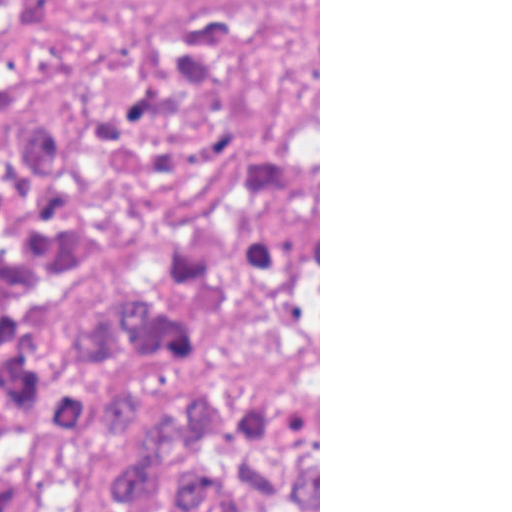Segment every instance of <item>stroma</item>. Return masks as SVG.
Here are the masks:
<instances>
[{
	"instance_id": "obj_1",
	"label": "stroma",
	"mask_w": 512,
	"mask_h": 512,
	"mask_svg": "<svg viewBox=\"0 0 512 512\" xmlns=\"http://www.w3.org/2000/svg\"><path fill=\"white\" fill-rule=\"evenodd\" d=\"M83 129L106 228L98 275L54 294L60 345L180 236L242 162L318 157L320 0H0V132Z\"/></svg>"
}]
</instances>
